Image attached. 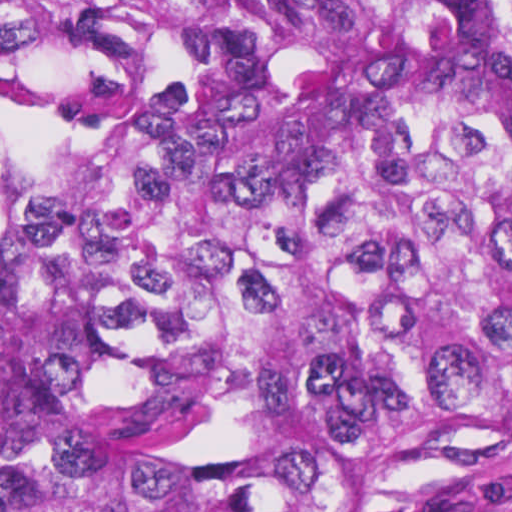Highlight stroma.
<instances>
[{"label":"stroma","mask_w":512,"mask_h":512,"mask_svg":"<svg viewBox=\"0 0 512 512\" xmlns=\"http://www.w3.org/2000/svg\"><path fill=\"white\" fill-rule=\"evenodd\" d=\"M380 512H512V450L457 467L422 495Z\"/></svg>","instance_id":"obj_1"}]
</instances>
